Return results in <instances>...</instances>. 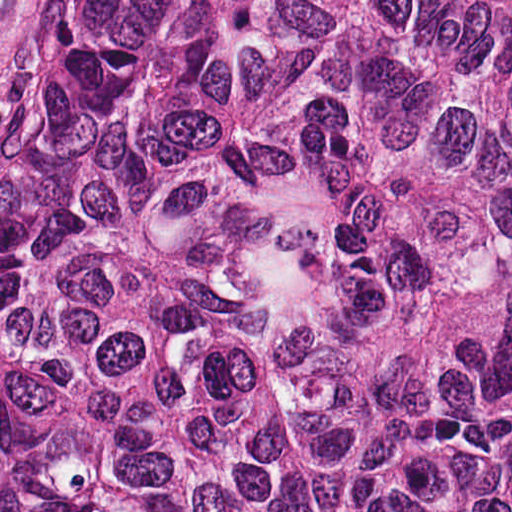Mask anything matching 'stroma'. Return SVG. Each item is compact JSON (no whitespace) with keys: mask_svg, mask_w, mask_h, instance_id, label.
<instances>
[{"mask_svg":"<svg viewBox=\"0 0 512 512\" xmlns=\"http://www.w3.org/2000/svg\"><path fill=\"white\" fill-rule=\"evenodd\" d=\"M88 0H3L0 9V184L15 127Z\"/></svg>","mask_w":512,"mask_h":512,"instance_id":"obj_1","label":"stroma"}]
</instances>
